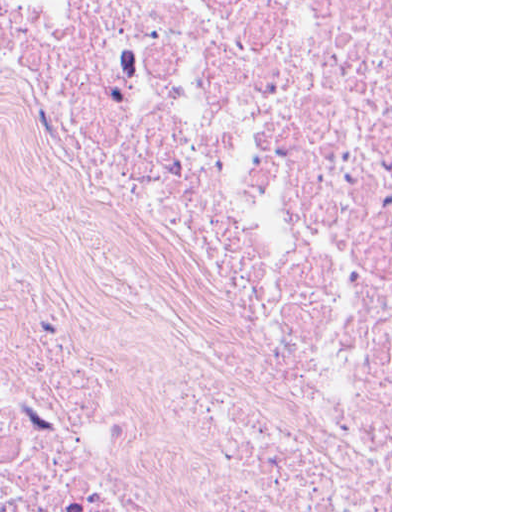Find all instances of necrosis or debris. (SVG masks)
I'll return each instance as SVG.
<instances>
[{"label": "necrosis or debris", "instance_id": "obj_1", "mask_svg": "<svg viewBox=\"0 0 512 512\" xmlns=\"http://www.w3.org/2000/svg\"><path fill=\"white\" fill-rule=\"evenodd\" d=\"M0 512H391V0H0Z\"/></svg>", "mask_w": 512, "mask_h": 512}]
</instances>
